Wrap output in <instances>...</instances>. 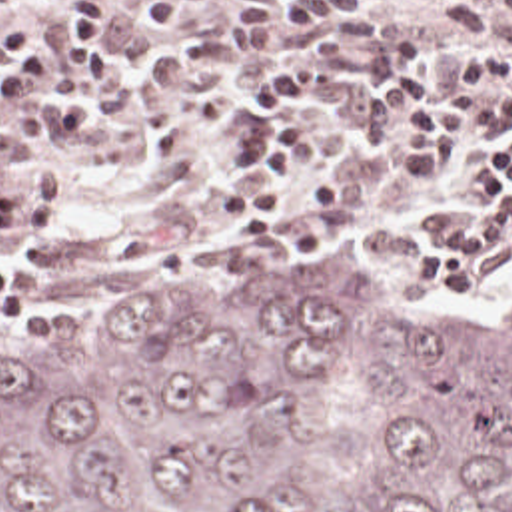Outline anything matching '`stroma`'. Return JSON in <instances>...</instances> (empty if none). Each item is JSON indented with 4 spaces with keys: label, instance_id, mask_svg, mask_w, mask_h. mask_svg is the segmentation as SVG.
Segmentation results:
<instances>
[{
    "label": "stroma",
    "instance_id": "stroma-1",
    "mask_svg": "<svg viewBox=\"0 0 512 512\" xmlns=\"http://www.w3.org/2000/svg\"><path fill=\"white\" fill-rule=\"evenodd\" d=\"M65 0H17L0 11V39L11 25L47 47L53 77L71 61L49 21ZM137 1V0H113ZM445 0H351L359 9L391 13ZM233 25V0H199L187 39H203ZM483 45H512V25ZM177 41L147 21L107 29L115 81L91 99L77 129H45L21 103L0 109V139L21 141L35 160L57 162L59 228L49 238L0 244V262L21 278V316H0V340L23 328H161L197 292L225 280L251 262L295 248L353 282H393L401 290L445 306L453 326L475 334L489 330L512 304V236L497 244L469 292H437L413 282L417 246L449 232L481 208L465 160L477 158L485 141L459 142L453 166L437 182L409 174L397 148L415 115L399 103L385 135L361 129L365 91L345 89L317 63L311 91L295 99L291 123L305 133L307 192L329 168L347 170V206L315 216H293L277 240L265 246H233L217 226V196L259 172L239 170L229 156L231 139L245 123V81L237 75L241 107L231 127H197L187 158H161L155 125L141 95L149 55L171 59ZM421 69L453 81L457 63L423 59Z\"/></svg>",
    "mask_w": 512,
    "mask_h": 512
}]
</instances>
